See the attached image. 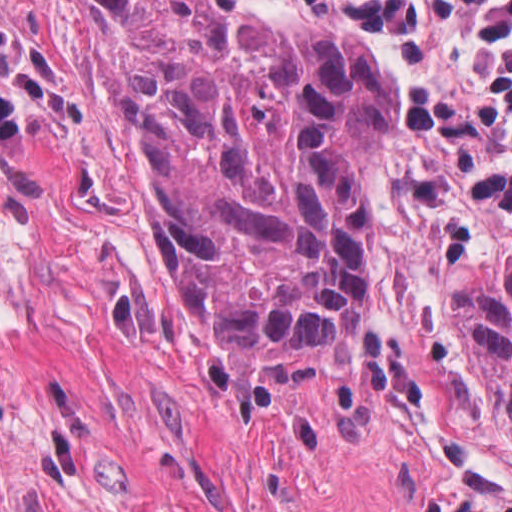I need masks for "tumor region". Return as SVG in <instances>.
<instances>
[{"instance_id":"1","label":"tumor region","mask_w":512,"mask_h":512,"mask_svg":"<svg viewBox=\"0 0 512 512\" xmlns=\"http://www.w3.org/2000/svg\"><path fill=\"white\" fill-rule=\"evenodd\" d=\"M235 1L369 229V161L386 126V62L342 29ZM458 346L512 444V260L480 268L458 293Z\"/></svg>"}]
</instances>
